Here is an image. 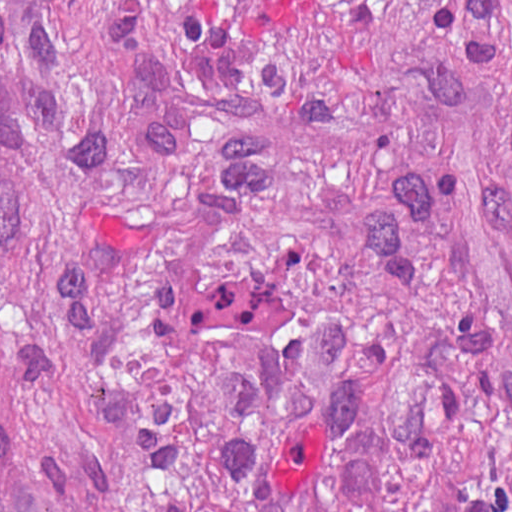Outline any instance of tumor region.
<instances>
[{
  "label": "tumor region",
  "instance_id": "tumor-region-1",
  "mask_svg": "<svg viewBox=\"0 0 512 512\" xmlns=\"http://www.w3.org/2000/svg\"><path fill=\"white\" fill-rule=\"evenodd\" d=\"M1 512H512V0H1Z\"/></svg>",
  "mask_w": 512,
  "mask_h": 512
}]
</instances>
